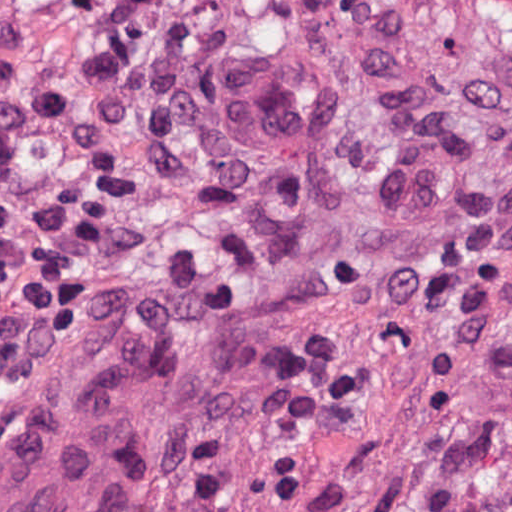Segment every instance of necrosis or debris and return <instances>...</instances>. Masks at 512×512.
Instances as JSON below:
<instances>
[{
  "mask_svg": "<svg viewBox=\"0 0 512 512\" xmlns=\"http://www.w3.org/2000/svg\"><path fill=\"white\" fill-rule=\"evenodd\" d=\"M245 59L320 74L401 145L482 63L404 0H0V118L48 158L52 268L108 270L204 214L206 96Z\"/></svg>",
  "mask_w": 512,
  "mask_h": 512,
  "instance_id": "obj_1",
  "label": "necrosis or debris"
}]
</instances>
